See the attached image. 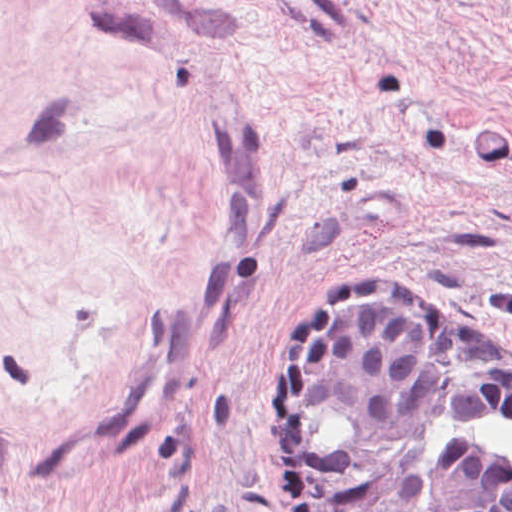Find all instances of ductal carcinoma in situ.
<instances>
[{"label": "ductal carcinoma in situ", "instance_id": "ductal-carcinoma-in-situ-1", "mask_svg": "<svg viewBox=\"0 0 512 512\" xmlns=\"http://www.w3.org/2000/svg\"><path fill=\"white\" fill-rule=\"evenodd\" d=\"M376 273L295 312L280 411L289 512H512V466L446 418L512 415V347L476 316Z\"/></svg>", "mask_w": 512, "mask_h": 512}]
</instances>
